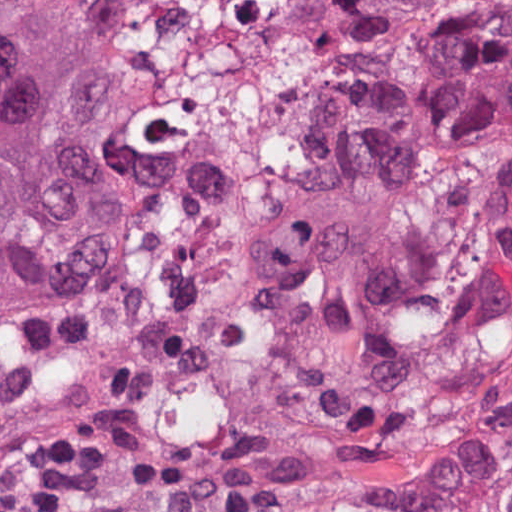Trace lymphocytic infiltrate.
I'll use <instances>...</instances> for the list:
<instances>
[{"mask_svg": "<svg viewBox=\"0 0 512 512\" xmlns=\"http://www.w3.org/2000/svg\"><path fill=\"white\" fill-rule=\"evenodd\" d=\"M125 425L96 414L79 418L52 443L29 488L9 512H57Z\"/></svg>", "mask_w": 512, "mask_h": 512, "instance_id": "1", "label": "lymphocytic infiltrate"}]
</instances>
